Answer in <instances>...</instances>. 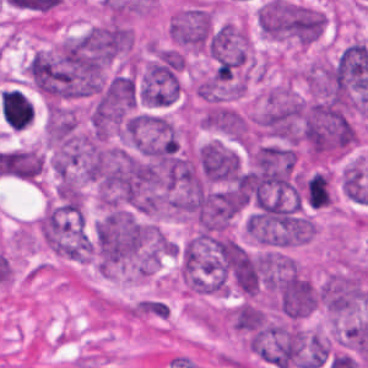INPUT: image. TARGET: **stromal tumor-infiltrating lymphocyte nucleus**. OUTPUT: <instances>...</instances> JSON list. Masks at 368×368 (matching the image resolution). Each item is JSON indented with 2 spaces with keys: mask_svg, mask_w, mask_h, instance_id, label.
<instances>
[{
  "mask_svg": "<svg viewBox=\"0 0 368 368\" xmlns=\"http://www.w3.org/2000/svg\"><path fill=\"white\" fill-rule=\"evenodd\" d=\"M0 110L8 126L20 130L32 122L34 114L32 102L17 89L0 92Z\"/></svg>",
  "mask_w": 368,
  "mask_h": 368,
  "instance_id": "stromal-tumor-infiltrating-lymphocyte-nucleus-1",
  "label": "stromal tumor-infiltrating lymphocyte nucleus"
}]
</instances>
